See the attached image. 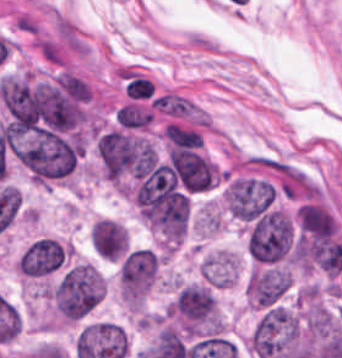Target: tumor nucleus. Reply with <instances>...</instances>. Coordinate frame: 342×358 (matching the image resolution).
<instances>
[{"label": "tumor nucleus", "mask_w": 342, "mask_h": 358, "mask_svg": "<svg viewBox=\"0 0 342 358\" xmlns=\"http://www.w3.org/2000/svg\"><path fill=\"white\" fill-rule=\"evenodd\" d=\"M89 244L98 256L120 260L127 245V233L117 220L98 218L89 227Z\"/></svg>", "instance_id": "obj_7"}, {"label": "tumor nucleus", "mask_w": 342, "mask_h": 358, "mask_svg": "<svg viewBox=\"0 0 342 358\" xmlns=\"http://www.w3.org/2000/svg\"><path fill=\"white\" fill-rule=\"evenodd\" d=\"M105 293L104 277L89 263L77 262L64 271L49 291L61 320L79 321L94 310Z\"/></svg>", "instance_id": "obj_1"}, {"label": "tumor nucleus", "mask_w": 342, "mask_h": 358, "mask_svg": "<svg viewBox=\"0 0 342 358\" xmlns=\"http://www.w3.org/2000/svg\"><path fill=\"white\" fill-rule=\"evenodd\" d=\"M96 151L104 175L119 180L136 171L147 154L146 139L117 128L97 134Z\"/></svg>", "instance_id": "obj_2"}, {"label": "tumor nucleus", "mask_w": 342, "mask_h": 358, "mask_svg": "<svg viewBox=\"0 0 342 358\" xmlns=\"http://www.w3.org/2000/svg\"><path fill=\"white\" fill-rule=\"evenodd\" d=\"M291 236L292 229L285 214L270 211L251 225L245 247L255 261H275L287 252Z\"/></svg>", "instance_id": "obj_3"}, {"label": "tumor nucleus", "mask_w": 342, "mask_h": 358, "mask_svg": "<svg viewBox=\"0 0 342 358\" xmlns=\"http://www.w3.org/2000/svg\"><path fill=\"white\" fill-rule=\"evenodd\" d=\"M157 272V256L148 249L125 255L119 269V295L126 306H138Z\"/></svg>", "instance_id": "obj_4"}, {"label": "tumor nucleus", "mask_w": 342, "mask_h": 358, "mask_svg": "<svg viewBox=\"0 0 342 358\" xmlns=\"http://www.w3.org/2000/svg\"><path fill=\"white\" fill-rule=\"evenodd\" d=\"M169 168L184 190L203 191L213 185L216 168L212 162L196 150L170 148Z\"/></svg>", "instance_id": "obj_5"}, {"label": "tumor nucleus", "mask_w": 342, "mask_h": 358, "mask_svg": "<svg viewBox=\"0 0 342 358\" xmlns=\"http://www.w3.org/2000/svg\"><path fill=\"white\" fill-rule=\"evenodd\" d=\"M290 284L289 273L280 267H260L245 281L248 304L260 311L280 304Z\"/></svg>", "instance_id": "obj_6"}, {"label": "tumor nucleus", "mask_w": 342, "mask_h": 358, "mask_svg": "<svg viewBox=\"0 0 342 358\" xmlns=\"http://www.w3.org/2000/svg\"><path fill=\"white\" fill-rule=\"evenodd\" d=\"M237 274L234 252L216 251L202 260L201 276L212 287H229Z\"/></svg>", "instance_id": "obj_8"}]
</instances>
